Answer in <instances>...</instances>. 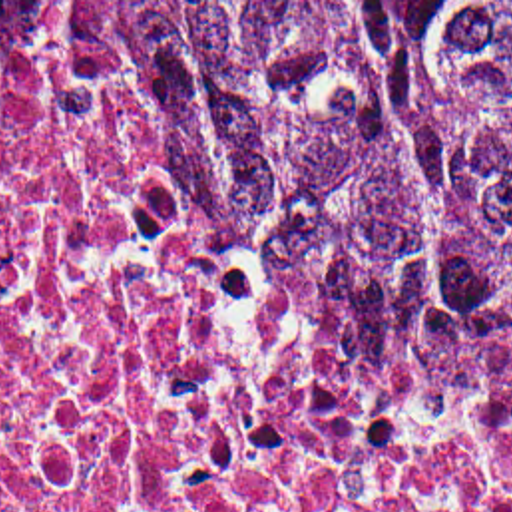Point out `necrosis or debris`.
<instances>
[{
	"label": "necrosis or debris",
	"mask_w": 512,
	"mask_h": 512,
	"mask_svg": "<svg viewBox=\"0 0 512 512\" xmlns=\"http://www.w3.org/2000/svg\"><path fill=\"white\" fill-rule=\"evenodd\" d=\"M0 512H512V392L399 360L135 38L0 34Z\"/></svg>",
	"instance_id": "obj_1"
}]
</instances>
